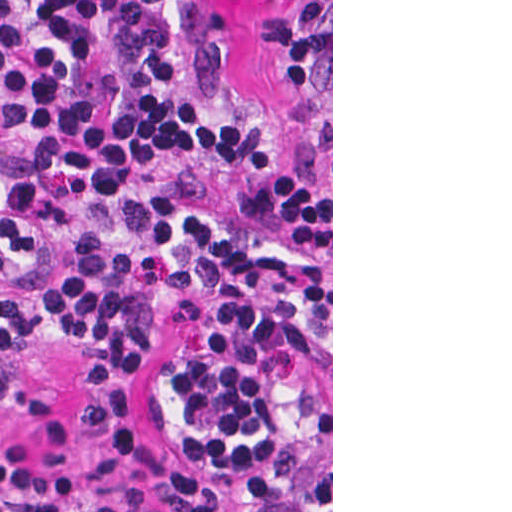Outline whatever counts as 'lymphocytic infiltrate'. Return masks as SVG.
Wrapping results in <instances>:
<instances>
[{
    "instance_id": "obj_1",
    "label": "lymphocytic infiltrate",
    "mask_w": 512,
    "mask_h": 512,
    "mask_svg": "<svg viewBox=\"0 0 512 512\" xmlns=\"http://www.w3.org/2000/svg\"><path fill=\"white\" fill-rule=\"evenodd\" d=\"M282 104L243 110L217 0H0V362L106 336L66 423L0 378V512H298L283 311L331 309V0H272ZM212 296L144 429L148 341Z\"/></svg>"
}]
</instances>
